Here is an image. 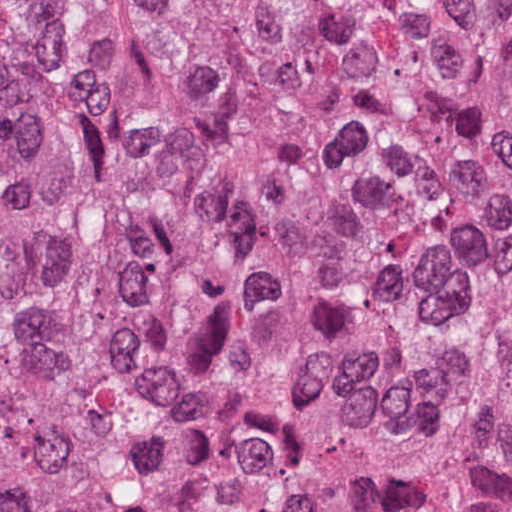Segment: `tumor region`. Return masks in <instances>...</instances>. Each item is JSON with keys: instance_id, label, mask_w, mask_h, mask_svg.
<instances>
[{"instance_id": "1", "label": "tumor region", "mask_w": 512, "mask_h": 512, "mask_svg": "<svg viewBox=\"0 0 512 512\" xmlns=\"http://www.w3.org/2000/svg\"><path fill=\"white\" fill-rule=\"evenodd\" d=\"M151 156L277 512H512V0H182ZM164 445L51 2L0 0V512H135Z\"/></svg>"}]
</instances>
